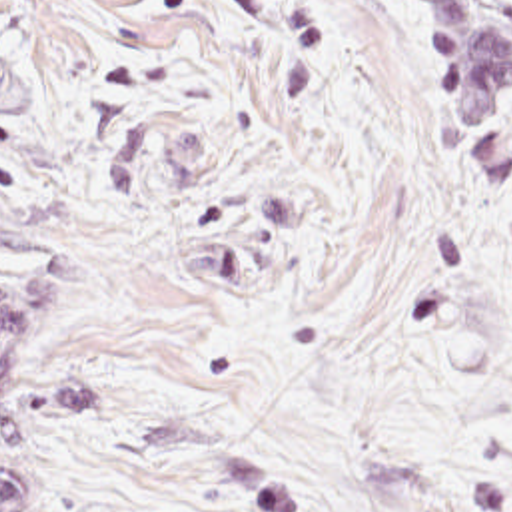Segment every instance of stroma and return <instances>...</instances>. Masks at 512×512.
<instances>
[{"label":"stroma","mask_w":512,"mask_h":512,"mask_svg":"<svg viewBox=\"0 0 512 512\" xmlns=\"http://www.w3.org/2000/svg\"><path fill=\"white\" fill-rule=\"evenodd\" d=\"M449 0H0L22 512H512Z\"/></svg>","instance_id":"35a3bbf8"}]
</instances>
